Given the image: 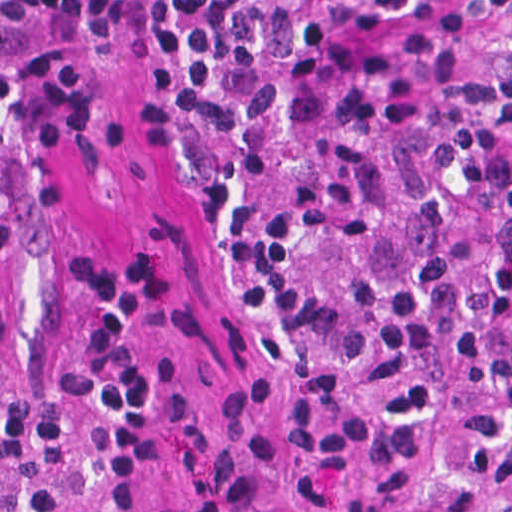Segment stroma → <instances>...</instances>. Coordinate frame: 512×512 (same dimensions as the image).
Listing matches in <instances>:
<instances>
[{"label": "stroma", "mask_w": 512, "mask_h": 512, "mask_svg": "<svg viewBox=\"0 0 512 512\" xmlns=\"http://www.w3.org/2000/svg\"><path fill=\"white\" fill-rule=\"evenodd\" d=\"M78 31V88L61 123L20 169L41 160L80 163L96 176L93 203L61 240L30 323L24 363L49 395L67 388V280L109 255H153L178 267L162 361L180 388L253 378L280 425L282 512H334L303 467L291 421L318 374L334 372L287 354L247 294L219 229L204 210L180 144L146 136L140 104L154 74L137 0H71ZM391 415L423 430L433 450L420 512H476L463 463L489 438L492 377L464 358H405L370 390ZM175 471L156 473L147 512H190ZM0 512H31L11 470L0 466ZM67 512H103L79 502Z\"/></svg>", "instance_id": "1"}]
</instances>
